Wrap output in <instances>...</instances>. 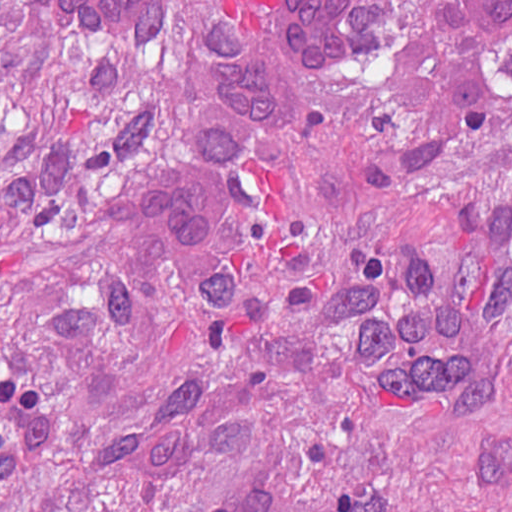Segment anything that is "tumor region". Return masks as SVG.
Returning <instances> with one entry per match:
<instances>
[{
  "instance_id": "obj_1",
  "label": "tumor region",
  "mask_w": 512,
  "mask_h": 512,
  "mask_svg": "<svg viewBox=\"0 0 512 512\" xmlns=\"http://www.w3.org/2000/svg\"><path fill=\"white\" fill-rule=\"evenodd\" d=\"M0 512H512V0H0Z\"/></svg>"
}]
</instances>
